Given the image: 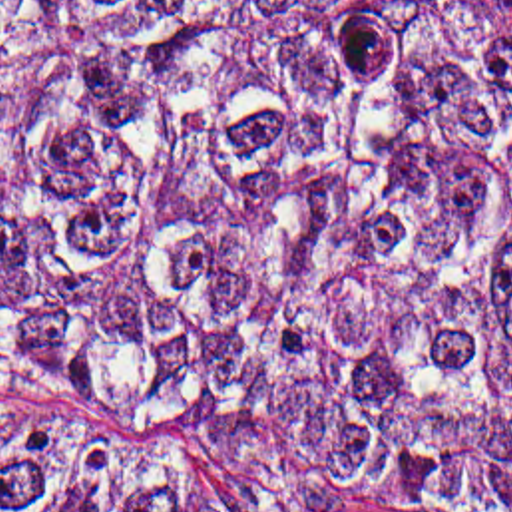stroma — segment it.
Instances as JSON below:
<instances>
[{
	"mask_svg": "<svg viewBox=\"0 0 512 512\" xmlns=\"http://www.w3.org/2000/svg\"><path fill=\"white\" fill-rule=\"evenodd\" d=\"M248 512H406L358 499H256Z\"/></svg>",
	"mask_w": 512,
	"mask_h": 512,
	"instance_id": "1",
	"label": "stroma"
}]
</instances>
